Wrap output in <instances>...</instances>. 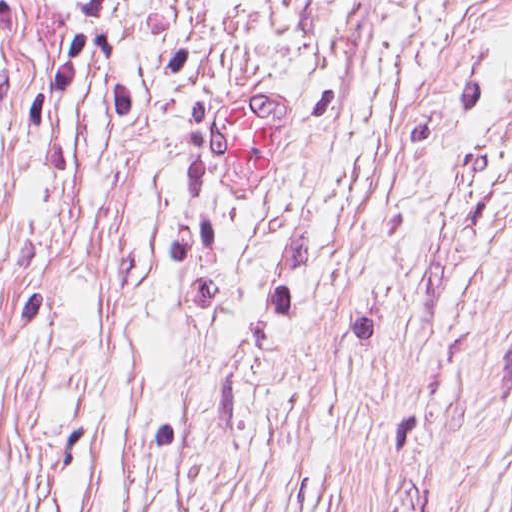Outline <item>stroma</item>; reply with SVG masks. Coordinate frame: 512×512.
<instances>
[{"label":"stroma","instance_id":"35a3bbf8","mask_svg":"<svg viewBox=\"0 0 512 512\" xmlns=\"http://www.w3.org/2000/svg\"><path fill=\"white\" fill-rule=\"evenodd\" d=\"M0 512H512V0H0Z\"/></svg>","mask_w":512,"mask_h":512}]
</instances>
